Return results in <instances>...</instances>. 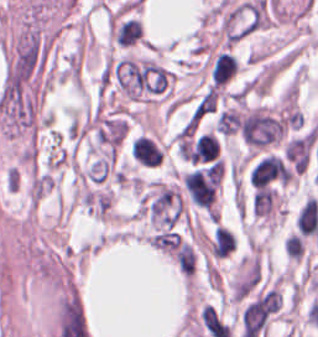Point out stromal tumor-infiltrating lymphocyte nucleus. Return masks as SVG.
<instances>
[{
    "instance_id": "stromal-tumor-infiltrating-lymphocyte-nucleus-1",
    "label": "stromal tumor-infiltrating lymphocyte nucleus",
    "mask_w": 318,
    "mask_h": 337,
    "mask_svg": "<svg viewBox=\"0 0 318 337\" xmlns=\"http://www.w3.org/2000/svg\"><path fill=\"white\" fill-rule=\"evenodd\" d=\"M238 65L228 52L218 54L212 63L211 76L215 85H223L236 73Z\"/></svg>"
},
{
    "instance_id": "stromal-tumor-infiltrating-lymphocyte-nucleus-2",
    "label": "stromal tumor-infiltrating lymphocyte nucleus",
    "mask_w": 318,
    "mask_h": 337,
    "mask_svg": "<svg viewBox=\"0 0 318 337\" xmlns=\"http://www.w3.org/2000/svg\"><path fill=\"white\" fill-rule=\"evenodd\" d=\"M142 24L140 19L128 18L117 25L114 33V41L119 45H133L140 37Z\"/></svg>"
}]
</instances>
